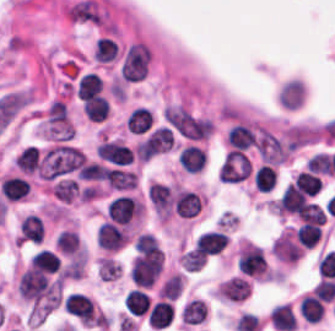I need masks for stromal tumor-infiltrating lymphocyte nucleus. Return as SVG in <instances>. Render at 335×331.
Here are the masks:
<instances>
[{
	"label": "stromal tumor-infiltrating lymphocyte nucleus",
	"instance_id": "bc302bb0",
	"mask_svg": "<svg viewBox=\"0 0 335 331\" xmlns=\"http://www.w3.org/2000/svg\"><path fill=\"white\" fill-rule=\"evenodd\" d=\"M163 257L135 254L130 264V277L136 286H151L162 268Z\"/></svg>",
	"mask_w": 335,
	"mask_h": 331
},
{
	"label": "stromal tumor-infiltrating lymphocyte nucleus",
	"instance_id": "52c7bb5b",
	"mask_svg": "<svg viewBox=\"0 0 335 331\" xmlns=\"http://www.w3.org/2000/svg\"><path fill=\"white\" fill-rule=\"evenodd\" d=\"M251 168L252 163L245 152L231 148L217 174L221 180L239 181L249 174Z\"/></svg>",
	"mask_w": 335,
	"mask_h": 331
},
{
	"label": "stromal tumor-infiltrating lymphocyte nucleus",
	"instance_id": "3290ff9b",
	"mask_svg": "<svg viewBox=\"0 0 335 331\" xmlns=\"http://www.w3.org/2000/svg\"><path fill=\"white\" fill-rule=\"evenodd\" d=\"M139 213V206L128 194H120L106 204V217L119 224H128Z\"/></svg>",
	"mask_w": 335,
	"mask_h": 331
},
{
	"label": "stromal tumor-infiltrating lymphocyte nucleus",
	"instance_id": "abfb95fc",
	"mask_svg": "<svg viewBox=\"0 0 335 331\" xmlns=\"http://www.w3.org/2000/svg\"><path fill=\"white\" fill-rule=\"evenodd\" d=\"M128 236L126 228L106 220L98 227L96 241L104 250L115 251L125 245Z\"/></svg>",
	"mask_w": 335,
	"mask_h": 331
},
{
	"label": "stromal tumor-infiltrating lymphocyte nucleus",
	"instance_id": "9ea309e8",
	"mask_svg": "<svg viewBox=\"0 0 335 331\" xmlns=\"http://www.w3.org/2000/svg\"><path fill=\"white\" fill-rule=\"evenodd\" d=\"M202 202L194 190L178 189L173 196V210L181 217H194Z\"/></svg>",
	"mask_w": 335,
	"mask_h": 331
},
{
	"label": "stromal tumor-infiltrating lymphocyte nucleus",
	"instance_id": "f3e2335f",
	"mask_svg": "<svg viewBox=\"0 0 335 331\" xmlns=\"http://www.w3.org/2000/svg\"><path fill=\"white\" fill-rule=\"evenodd\" d=\"M227 240L226 232L210 228L199 233L194 246L199 254H212L221 249Z\"/></svg>",
	"mask_w": 335,
	"mask_h": 331
},
{
	"label": "stromal tumor-infiltrating lymphocyte nucleus",
	"instance_id": "4f13568d",
	"mask_svg": "<svg viewBox=\"0 0 335 331\" xmlns=\"http://www.w3.org/2000/svg\"><path fill=\"white\" fill-rule=\"evenodd\" d=\"M206 155L204 148L187 144L181 148L177 160L184 172H197L203 165Z\"/></svg>",
	"mask_w": 335,
	"mask_h": 331
},
{
	"label": "stromal tumor-infiltrating lymphocyte nucleus",
	"instance_id": "2a367800",
	"mask_svg": "<svg viewBox=\"0 0 335 331\" xmlns=\"http://www.w3.org/2000/svg\"><path fill=\"white\" fill-rule=\"evenodd\" d=\"M104 179L112 189H131L136 181V174L128 169L108 167L104 172Z\"/></svg>",
	"mask_w": 335,
	"mask_h": 331
},
{
	"label": "stromal tumor-infiltrating lymphocyte nucleus",
	"instance_id": "4803ca6d",
	"mask_svg": "<svg viewBox=\"0 0 335 331\" xmlns=\"http://www.w3.org/2000/svg\"><path fill=\"white\" fill-rule=\"evenodd\" d=\"M271 328L279 331H291L295 321L291 308L285 303L274 304L268 313Z\"/></svg>",
	"mask_w": 335,
	"mask_h": 331
},
{
	"label": "stromal tumor-infiltrating lymphocyte nucleus",
	"instance_id": "4245b91a",
	"mask_svg": "<svg viewBox=\"0 0 335 331\" xmlns=\"http://www.w3.org/2000/svg\"><path fill=\"white\" fill-rule=\"evenodd\" d=\"M173 317V305L166 299H158L154 302L147 314V323L155 328H164Z\"/></svg>",
	"mask_w": 335,
	"mask_h": 331
},
{
	"label": "stromal tumor-infiltrating lymphocyte nucleus",
	"instance_id": "4c9ddf68",
	"mask_svg": "<svg viewBox=\"0 0 335 331\" xmlns=\"http://www.w3.org/2000/svg\"><path fill=\"white\" fill-rule=\"evenodd\" d=\"M0 184L4 199L22 200L29 193L28 183L20 175H6Z\"/></svg>",
	"mask_w": 335,
	"mask_h": 331
},
{
	"label": "stromal tumor-infiltrating lymphocyte nucleus",
	"instance_id": "2761f720",
	"mask_svg": "<svg viewBox=\"0 0 335 331\" xmlns=\"http://www.w3.org/2000/svg\"><path fill=\"white\" fill-rule=\"evenodd\" d=\"M253 143L254 130L247 124L238 121L227 132V145L242 149Z\"/></svg>",
	"mask_w": 335,
	"mask_h": 331
},
{
	"label": "stromal tumor-infiltrating lymphocyte nucleus",
	"instance_id": "3c572f05",
	"mask_svg": "<svg viewBox=\"0 0 335 331\" xmlns=\"http://www.w3.org/2000/svg\"><path fill=\"white\" fill-rule=\"evenodd\" d=\"M82 113L90 120H103L108 113V103L102 94L86 97L81 102Z\"/></svg>",
	"mask_w": 335,
	"mask_h": 331
},
{
	"label": "stromal tumor-infiltrating lymphocyte nucleus",
	"instance_id": "42bb06b2",
	"mask_svg": "<svg viewBox=\"0 0 335 331\" xmlns=\"http://www.w3.org/2000/svg\"><path fill=\"white\" fill-rule=\"evenodd\" d=\"M298 310L307 323H317L324 308L311 292L301 296Z\"/></svg>",
	"mask_w": 335,
	"mask_h": 331
},
{
	"label": "stromal tumor-infiltrating lymphocyte nucleus",
	"instance_id": "9e4306bb",
	"mask_svg": "<svg viewBox=\"0 0 335 331\" xmlns=\"http://www.w3.org/2000/svg\"><path fill=\"white\" fill-rule=\"evenodd\" d=\"M152 121L153 116L151 110L139 105L131 110L125 124L131 132L142 133L150 129Z\"/></svg>",
	"mask_w": 335,
	"mask_h": 331
},
{
	"label": "stromal tumor-infiltrating lymphocyte nucleus",
	"instance_id": "04cf8593",
	"mask_svg": "<svg viewBox=\"0 0 335 331\" xmlns=\"http://www.w3.org/2000/svg\"><path fill=\"white\" fill-rule=\"evenodd\" d=\"M124 307L133 314H142L150 307L147 293L139 288H131L123 299Z\"/></svg>",
	"mask_w": 335,
	"mask_h": 331
},
{
	"label": "stromal tumor-infiltrating lymphocyte nucleus",
	"instance_id": "e9af9c67",
	"mask_svg": "<svg viewBox=\"0 0 335 331\" xmlns=\"http://www.w3.org/2000/svg\"><path fill=\"white\" fill-rule=\"evenodd\" d=\"M134 246L136 250L151 259H160L162 256V249L153 234L148 232H141L135 239Z\"/></svg>",
	"mask_w": 335,
	"mask_h": 331
},
{
	"label": "stromal tumor-infiltrating lymphocyte nucleus",
	"instance_id": "782c7336",
	"mask_svg": "<svg viewBox=\"0 0 335 331\" xmlns=\"http://www.w3.org/2000/svg\"><path fill=\"white\" fill-rule=\"evenodd\" d=\"M14 163L23 172H33L39 165L38 147L26 145L16 155Z\"/></svg>",
	"mask_w": 335,
	"mask_h": 331
},
{
	"label": "stromal tumor-infiltrating lymphocyte nucleus",
	"instance_id": "cac63f63",
	"mask_svg": "<svg viewBox=\"0 0 335 331\" xmlns=\"http://www.w3.org/2000/svg\"><path fill=\"white\" fill-rule=\"evenodd\" d=\"M276 181L275 169L270 164H262L253 174V184L257 190L268 191Z\"/></svg>",
	"mask_w": 335,
	"mask_h": 331
},
{
	"label": "stromal tumor-infiltrating lymphocyte nucleus",
	"instance_id": "2e467ee5",
	"mask_svg": "<svg viewBox=\"0 0 335 331\" xmlns=\"http://www.w3.org/2000/svg\"><path fill=\"white\" fill-rule=\"evenodd\" d=\"M118 44L107 35H100L95 44L93 56L95 60H114Z\"/></svg>",
	"mask_w": 335,
	"mask_h": 331
},
{
	"label": "stromal tumor-infiltrating lymphocyte nucleus",
	"instance_id": "7eef579d",
	"mask_svg": "<svg viewBox=\"0 0 335 331\" xmlns=\"http://www.w3.org/2000/svg\"><path fill=\"white\" fill-rule=\"evenodd\" d=\"M296 242L303 246L312 247V245L320 237L318 226L311 222H303L294 232Z\"/></svg>",
	"mask_w": 335,
	"mask_h": 331
},
{
	"label": "stromal tumor-infiltrating lymphocyte nucleus",
	"instance_id": "c26a33f6",
	"mask_svg": "<svg viewBox=\"0 0 335 331\" xmlns=\"http://www.w3.org/2000/svg\"><path fill=\"white\" fill-rule=\"evenodd\" d=\"M311 292L322 302H329L335 295L334 277H321L313 286Z\"/></svg>",
	"mask_w": 335,
	"mask_h": 331
},
{
	"label": "stromal tumor-infiltrating lymphocyte nucleus",
	"instance_id": "3e0999b9",
	"mask_svg": "<svg viewBox=\"0 0 335 331\" xmlns=\"http://www.w3.org/2000/svg\"><path fill=\"white\" fill-rule=\"evenodd\" d=\"M52 194L69 202L77 194L76 180L69 178L58 179L52 187Z\"/></svg>",
	"mask_w": 335,
	"mask_h": 331
},
{
	"label": "stromal tumor-infiltrating lymphocyte nucleus",
	"instance_id": "a0a3295f",
	"mask_svg": "<svg viewBox=\"0 0 335 331\" xmlns=\"http://www.w3.org/2000/svg\"><path fill=\"white\" fill-rule=\"evenodd\" d=\"M56 246L65 254H73L78 246V236L75 230H61L55 240Z\"/></svg>",
	"mask_w": 335,
	"mask_h": 331
},
{
	"label": "stromal tumor-infiltrating lymphocyte nucleus",
	"instance_id": "b6af03f8",
	"mask_svg": "<svg viewBox=\"0 0 335 331\" xmlns=\"http://www.w3.org/2000/svg\"><path fill=\"white\" fill-rule=\"evenodd\" d=\"M297 214L301 222L324 223L325 214L319 204L306 202Z\"/></svg>",
	"mask_w": 335,
	"mask_h": 331
},
{
	"label": "stromal tumor-infiltrating lymphocyte nucleus",
	"instance_id": "6c763739",
	"mask_svg": "<svg viewBox=\"0 0 335 331\" xmlns=\"http://www.w3.org/2000/svg\"><path fill=\"white\" fill-rule=\"evenodd\" d=\"M294 180L312 196L318 192L322 182L319 176L306 169L297 174Z\"/></svg>",
	"mask_w": 335,
	"mask_h": 331
},
{
	"label": "stromal tumor-infiltrating lymphocyte nucleus",
	"instance_id": "fa64b396",
	"mask_svg": "<svg viewBox=\"0 0 335 331\" xmlns=\"http://www.w3.org/2000/svg\"><path fill=\"white\" fill-rule=\"evenodd\" d=\"M309 167L318 174H330L329 160L325 153L315 152L308 158Z\"/></svg>",
	"mask_w": 335,
	"mask_h": 331
}]
</instances>
